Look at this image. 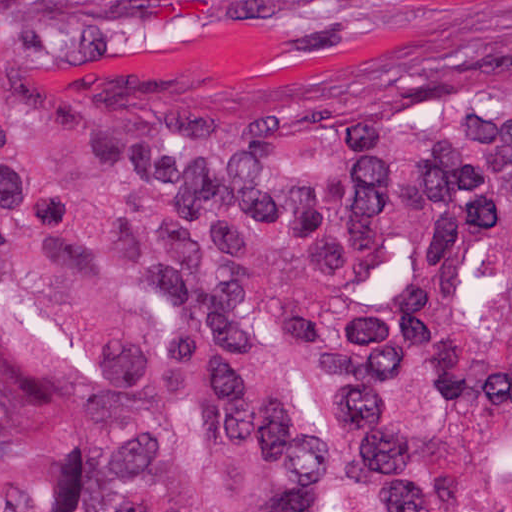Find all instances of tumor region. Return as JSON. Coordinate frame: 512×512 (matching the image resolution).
Segmentation results:
<instances>
[{"mask_svg": "<svg viewBox=\"0 0 512 512\" xmlns=\"http://www.w3.org/2000/svg\"><path fill=\"white\" fill-rule=\"evenodd\" d=\"M0 512H512V0L229 71L0 0Z\"/></svg>", "mask_w": 512, "mask_h": 512, "instance_id": "tumor-region-1", "label": "tumor region"}]
</instances>
